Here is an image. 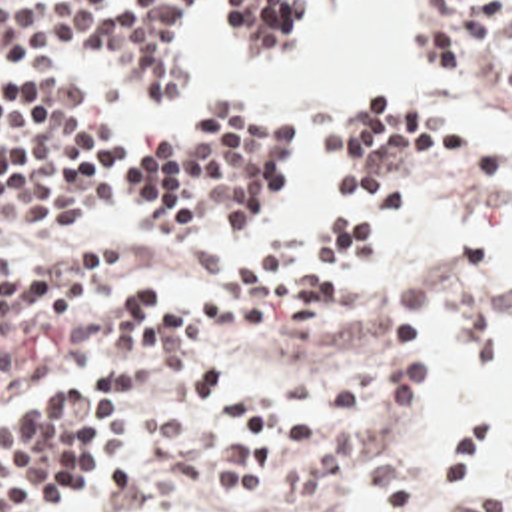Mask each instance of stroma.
Returning <instances> with one entry per match:
<instances>
[{
    "label": "stroma",
    "mask_w": 512,
    "mask_h": 512,
    "mask_svg": "<svg viewBox=\"0 0 512 512\" xmlns=\"http://www.w3.org/2000/svg\"><path fill=\"white\" fill-rule=\"evenodd\" d=\"M349 2H317L311 26L283 55L243 57H293ZM407 2L427 37V0ZM215 4L207 0L189 20L183 95L129 93L119 99L139 131L161 133L177 113L195 105L189 101L207 65L197 41H213ZM455 69L479 87L493 119L512 131L511 97L491 79ZM363 101L347 93L315 111L243 107L289 121L291 155L247 215L225 231L149 227L123 215H53L0 235V273L21 269L81 235L129 237L163 249L235 241L255 263H279L311 225L319 133ZM413 105L457 131V165L449 189L397 229L363 275L335 351L249 355L171 347L121 371L89 367L97 373V391L123 405V443L99 481H111L101 512H337L361 463L401 429L419 363L445 317L485 363L495 345V227L483 209L487 187L453 113L435 103ZM457 415L491 425L497 485L512 497V443L507 445L503 423L489 411ZM459 489L443 483L433 439L415 512H455Z\"/></svg>",
    "instance_id": "1"
}]
</instances>
